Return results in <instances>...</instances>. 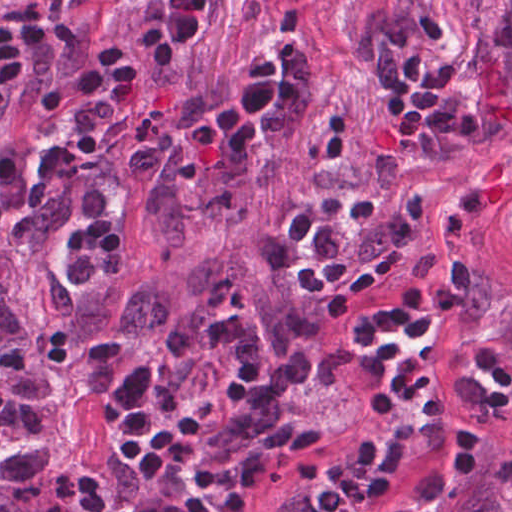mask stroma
<instances>
[{
  "label": "stroma",
  "instance_id": "obj_1",
  "mask_svg": "<svg viewBox=\"0 0 512 512\" xmlns=\"http://www.w3.org/2000/svg\"><path fill=\"white\" fill-rule=\"evenodd\" d=\"M473 260L484 283L512 288V174L422 273L453 275ZM421 274V275H422ZM459 313L437 326L424 352L409 351L438 392L433 421L373 420L362 404L358 365L342 361L207 512H312L329 483L378 479L388 452H406L395 491L372 512H424L459 471L473 445H497L500 466L512 438V366L492 318L462 336Z\"/></svg>",
  "mask_w": 512,
  "mask_h": 512
}]
</instances>
